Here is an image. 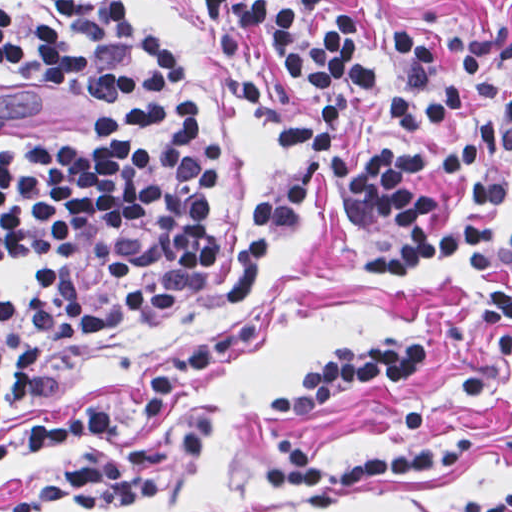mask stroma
I'll list each match as a JSON object with an SVG mask.
<instances>
[{
    "label": "stroma",
    "mask_w": 512,
    "mask_h": 512,
    "mask_svg": "<svg viewBox=\"0 0 512 512\" xmlns=\"http://www.w3.org/2000/svg\"><path fill=\"white\" fill-rule=\"evenodd\" d=\"M137 23L152 27L174 51L200 104L204 129L220 148L211 225L224 239L205 279L169 321L93 349L51 371L55 383L29 418H60L104 403L115 415L69 439L71 457L122 450L129 442L139 393L164 363L220 331L227 286L243 248L248 216L260 202L302 179L310 200L277 243L249 308L260 331L243 357L187 396L163 423V484L156 498L118 512H454L496 495L512 482V372L499 359L496 331L484 328L488 278L455 257L381 274L357 260L403 245L405 228L390 219L359 222L339 205L332 167L308 148L283 143L233 86L260 68L270 106L311 119L324 104L342 114L341 150L373 162L396 143L456 194L466 174L449 180L436 163L453 145L434 125L399 130L394 95L361 97L307 88L284 70L268 39L250 32L226 70L209 16L197 0H124ZM359 17L383 93L403 92L388 61L372 0H326ZM389 28L421 36L450 65L462 30H512V0H377ZM98 102L60 94L1 64L0 0V433L15 426L1 386V141L44 136L77 146L94 142ZM485 171L508 179L511 199L497 210L499 235L512 222V145L482 149ZM396 334L428 348L424 372L398 384L367 383L310 414L270 411V400L299 394L309 370L332 350L360 349ZM423 409L435 437L470 432L476 446L454 471L419 478L381 477L350 487L340 502L308 509L297 492L272 488L266 467L278 463L271 442L293 436L325 466L412 454L404 416ZM49 451L0 468V512L47 470ZM65 512V511H59Z\"/></svg>",
    "instance_id": "obj_1"
}]
</instances>
